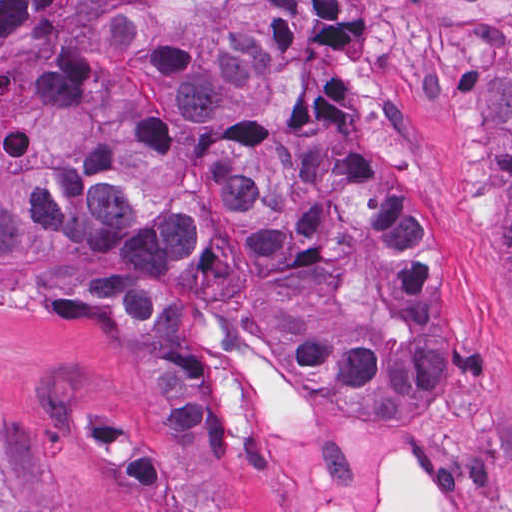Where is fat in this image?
Wrapping results in <instances>:
<instances>
[{"instance_id":"53f6f03d","label":"fat","mask_w":512,"mask_h":512,"mask_svg":"<svg viewBox=\"0 0 512 512\" xmlns=\"http://www.w3.org/2000/svg\"><path fill=\"white\" fill-rule=\"evenodd\" d=\"M331 501L319 512H349ZM375 512H444L432 499L429 483L414 461H398L391 472V461L383 487L377 497Z\"/></svg>"}]
</instances>
